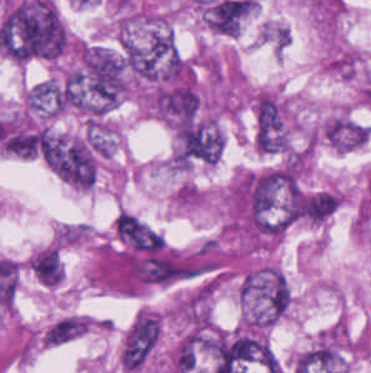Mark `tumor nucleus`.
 Here are the masks:
<instances>
[{
  "label": "tumor nucleus",
  "mask_w": 371,
  "mask_h": 373,
  "mask_svg": "<svg viewBox=\"0 0 371 373\" xmlns=\"http://www.w3.org/2000/svg\"><path fill=\"white\" fill-rule=\"evenodd\" d=\"M238 296L243 324L267 327L283 316L292 292L281 269L262 264L243 275Z\"/></svg>",
  "instance_id": "tumor-nucleus-1"
},
{
  "label": "tumor nucleus",
  "mask_w": 371,
  "mask_h": 373,
  "mask_svg": "<svg viewBox=\"0 0 371 373\" xmlns=\"http://www.w3.org/2000/svg\"><path fill=\"white\" fill-rule=\"evenodd\" d=\"M159 319L153 312L141 310L123 335L118 363L126 372L133 373L143 366L157 345Z\"/></svg>",
  "instance_id": "tumor-nucleus-2"
},
{
  "label": "tumor nucleus",
  "mask_w": 371,
  "mask_h": 373,
  "mask_svg": "<svg viewBox=\"0 0 371 373\" xmlns=\"http://www.w3.org/2000/svg\"><path fill=\"white\" fill-rule=\"evenodd\" d=\"M321 133L330 146L346 152L362 146L368 138L367 126L347 113L328 118Z\"/></svg>",
  "instance_id": "tumor-nucleus-3"
},
{
  "label": "tumor nucleus",
  "mask_w": 371,
  "mask_h": 373,
  "mask_svg": "<svg viewBox=\"0 0 371 373\" xmlns=\"http://www.w3.org/2000/svg\"><path fill=\"white\" fill-rule=\"evenodd\" d=\"M24 103L28 112L55 116L65 108V86L56 80H43L27 89Z\"/></svg>",
  "instance_id": "tumor-nucleus-4"
},
{
  "label": "tumor nucleus",
  "mask_w": 371,
  "mask_h": 373,
  "mask_svg": "<svg viewBox=\"0 0 371 373\" xmlns=\"http://www.w3.org/2000/svg\"><path fill=\"white\" fill-rule=\"evenodd\" d=\"M28 268L43 286H55L63 277V266L56 246L44 245L28 262Z\"/></svg>",
  "instance_id": "tumor-nucleus-5"
},
{
  "label": "tumor nucleus",
  "mask_w": 371,
  "mask_h": 373,
  "mask_svg": "<svg viewBox=\"0 0 371 373\" xmlns=\"http://www.w3.org/2000/svg\"><path fill=\"white\" fill-rule=\"evenodd\" d=\"M86 331V316L79 314L65 315L54 322L42 336L47 346H60L77 339Z\"/></svg>",
  "instance_id": "tumor-nucleus-6"
}]
</instances>
